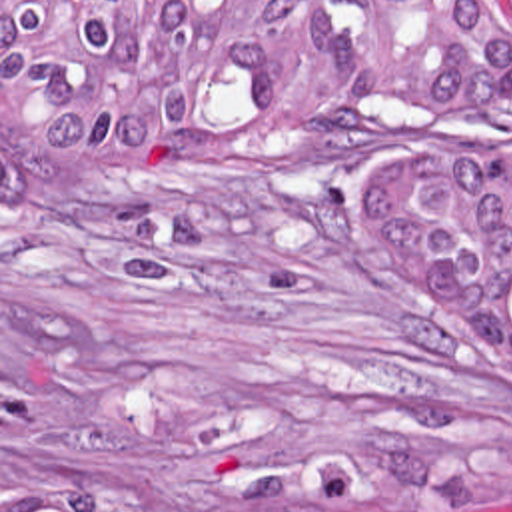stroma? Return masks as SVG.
Returning a JSON list of instances; mask_svg holds the SVG:
<instances>
[{
  "label": "stroma",
  "mask_w": 512,
  "mask_h": 512,
  "mask_svg": "<svg viewBox=\"0 0 512 512\" xmlns=\"http://www.w3.org/2000/svg\"><path fill=\"white\" fill-rule=\"evenodd\" d=\"M483 2L512 40V0ZM423 144L512 154V88L447 132L353 112L40 176L2 210L0 0V512L2 481L282 512L315 461H357L393 512H512V422L353 210L367 166Z\"/></svg>",
  "instance_id": "stroma-1"
}]
</instances>
